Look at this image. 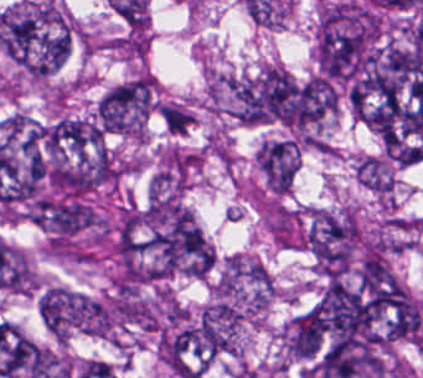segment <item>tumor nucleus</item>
Here are the masks:
<instances>
[{"label": "tumor nucleus", "mask_w": 423, "mask_h": 378, "mask_svg": "<svg viewBox=\"0 0 423 378\" xmlns=\"http://www.w3.org/2000/svg\"><path fill=\"white\" fill-rule=\"evenodd\" d=\"M138 248L163 279L203 276L213 264L201 230L177 203H151Z\"/></svg>", "instance_id": "2f306a5c"}, {"label": "tumor nucleus", "mask_w": 423, "mask_h": 378, "mask_svg": "<svg viewBox=\"0 0 423 378\" xmlns=\"http://www.w3.org/2000/svg\"><path fill=\"white\" fill-rule=\"evenodd\" d=\"M86 308V296L62 285H49L43 291L38 314L55 340L66 341L85 327Z\"/></svg>", "instance_id": "8643909e"}, {"label": "tumor nucleus", "mask_w": 423, "mask_h": 378, "mask_svg": "<svg viewBox=\"0 0 423 378\" xmlns=\"http://www.w3.org/2000/svg\"><path fill=\"white\" fill-rule=\"evenodd\" d=\"M35 222L56 237H70L92 223L90 208L76 199L41 201L35 205Z\"/></svg>", "instance_id": "5ab6c2c4"}, {"label": "tumor nucleus", "mask_w": 423, "mask_h": 378, "mask_svg": "<svg viewBox=\"0 0 423 378\" xmlns=\"http://www.w3.org/2000/svg\"><path fill=\"white\" fill-rule=\"evenodd\" d=\"M357 181L379 193H389L393 188L390 174L383 162L365 157L357 165Z\"/></svg>", "instance_id": "2cbd58db"}, {"label": "tumor nucleus", "mask_w": 423, "mask_h": 378, "mask_svg": "<svg viewBox=\"0 0 423 378\" xmlns=\"http://www.w3.org/2000/svg\"><path fill=\"white\" fill-rule=\"evenodd\" d=\"M158 111L165 126L171 133H184L189 126V111L175 105L162 104Z\"/></svg>", "instance_id": "3d1891a8"}]
</instances>
